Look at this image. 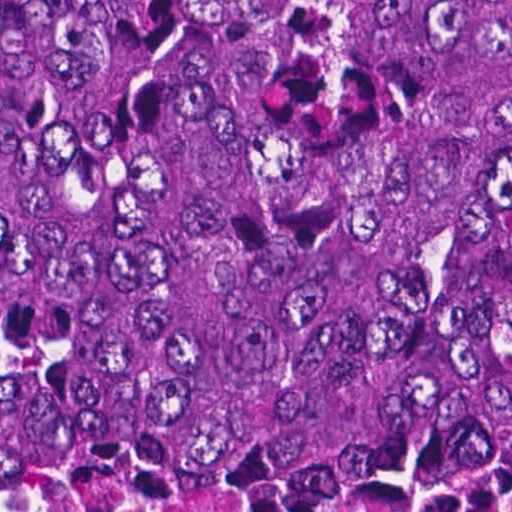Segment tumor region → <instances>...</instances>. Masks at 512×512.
<instances>
[{
  "label": "tumor region",
  "instance_id": "obj_1",
  "mask_svg": "<svg viewBox=\"0 0 512 512\" xmlns=\"http://www.w3.org/2000/svg\"><path fill=\"white\" fill-rule=\"evenodd\" d=\"M0 509L512 510V0H0Z\"/></svg>",
  "mask_w": 512,
  "mask_h": 512
}]
</instances>
